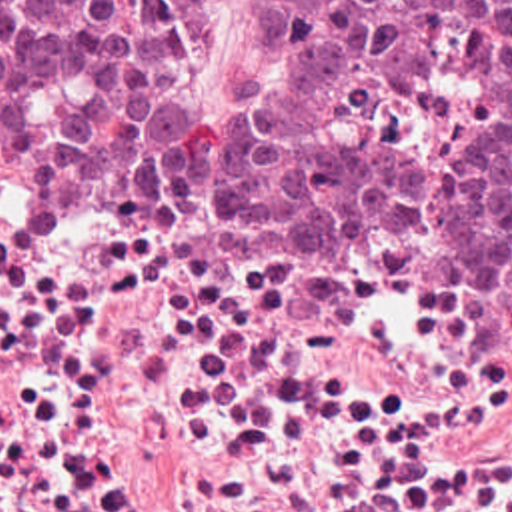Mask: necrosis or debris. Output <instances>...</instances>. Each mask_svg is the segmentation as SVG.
<instances>
[{
  "label": "necrosis or debris",
  "mask_w": 512,
  "mask_h": 512,
  "mask_svg": "<svg viewBox=\"0 0 512 512\" xmlns=\"http://www.w3.org/2000/svg\"><path fill=\"white\" fill-rule=\"evenodd\" d=\"M0 428H346V230L102 190L0 92Z\"/></svg>",
  "instance_id": "1"
}]
</instances>
